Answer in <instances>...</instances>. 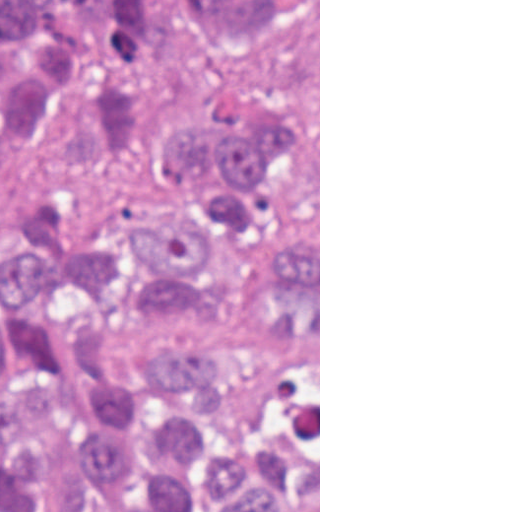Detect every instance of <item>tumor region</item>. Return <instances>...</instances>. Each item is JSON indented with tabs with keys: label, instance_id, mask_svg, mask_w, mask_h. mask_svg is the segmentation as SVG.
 Here are the masks:
<instances>
[{
	"label": "tumor region",
	"instance_id": "e687c5a6",
	"mask_svg": "<svg viewBox=\"0 0 512 512\" xmlns=\"http://www.w3.org/2000/svg\"><path fill=\"white\" fill-rule=\"evenodd\" d=\"M0 512H319V0H0Z\"/></svg>",
	"mask_w": 512,
	"mask_h": 512
}]
</instances>
